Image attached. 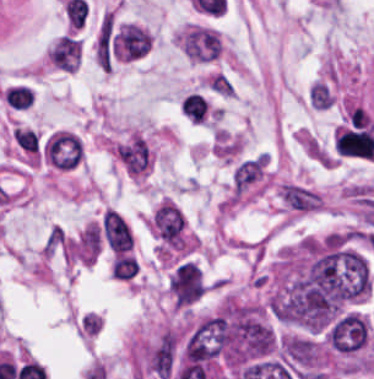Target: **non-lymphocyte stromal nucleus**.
Segmentation results:
<instances>
[{
    "label": "non-lymphocyte stromal nucleus",
    "mask_w": 374,
    "mask_h": 379,
    "mask_svg": "<svg viewBox=\"0 0 374 379\" xmlns=\"http://www.w3.org/2000/svg\"><path fill=\"white\" fill-rule=\"evenodd\" d=\"M265 172V154L240 161L232 173V191L243 193L260 181Z\"/></svg>",
    "instance_id": "3746e769"
},
{
    "label": "non-lymphocyte stromal nucleus",
    "mask_w": 374,
    "mask_h": 379,
    "mask_svg": "<svg viewBox=\"0 0 374 379\" xmlns=\"http://www.w3.org/2000/svg\"><path fill=\"white\" fill-rule=\"evenodd\" d=\"M102 230L108 247L122 253L129 250L133 237L124 219L115 210L106 209Z\"/></svg>",
    "instance_id": "a72fc3eb"
},
{
    "label": "non-lymphocyte stromal nucleus",
    "mask_w": 374,
    "mask_h": 379,
    "mask_svg": "<svg viewBox=\"0 0 374 379\" xmlns=\"http://www.w3.org/2000/svg\"><path fill=\"white\" fill-rule=\"evenodd\" d=\"M176 354L174 337L167 331L147 350L144 364L151 375L169 379L176 364Z\"/></svg>",
    "instance_id": "dd21d789"
},
{
    "label": "non-lymphocyte stromal nucleus",
    "mask_w": 374,
    "mask_h": 379,
    "mask_svg": "<svg viewBox=\"0 0 374 379\" xmlns=\"http://www.w3.org/2000/svg\"><path fill=\"white\" fill-rule=\"evenodd\" d=\"M321 197L306 186L284 183L281 202L293 211H313Z\"/></svg>",
    "instance_id": "fc2b8d12"
}]
</instances>
